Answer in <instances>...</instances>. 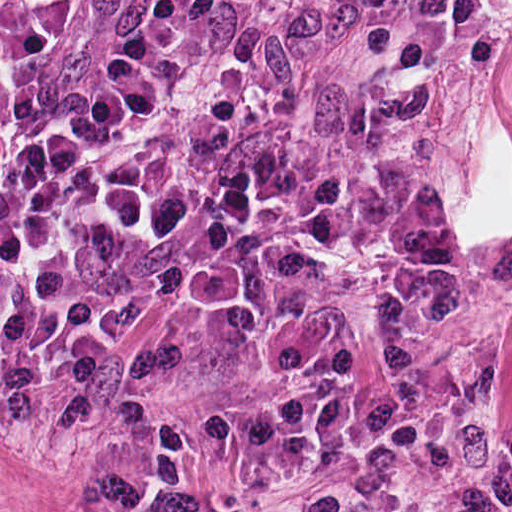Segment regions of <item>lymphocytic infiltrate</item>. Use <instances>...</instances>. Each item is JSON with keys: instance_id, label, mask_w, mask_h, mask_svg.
<instances>
[{"instance_id": "f902f5d3", "label": "lymphocytic infiltrate", "mask_w": 512, "mask_h": 512, "mask_svg": "<svg viewBox=\"0 0 512 512\" xmlns=\"http://www.w3.org/2000/svg\"><path fill=\"white\" fill-rule=\"evenodd\" d=\"M97 0H0V92ZM202 0H137L49 111L0 123V423L58 426L109 376L114 261L177 228L165 187L111 156L159 108Z\"/></svg>"}]
</instances>
